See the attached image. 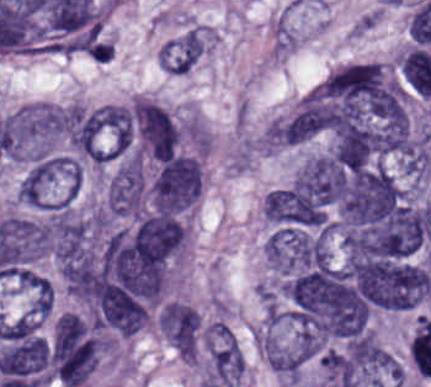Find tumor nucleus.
Masks as SVG:
<instances>
[{
  "label": "tumor nucleus",
  "mask_w": 431,
  "mask_h": 387,
  "mask_svg": "<svg viewBox=\"0 0 431 387\" xmlns=\"http://www.w3.org/2000/svg\"><path fill=\"white\" fill-rule=\"evenodd\" d=\"M196 156L174 153L158 159L144 188L154 212L189 214L194 207Z\"/></svg>",
  "instance_id": "1"
},
{
  "label": "tumor nucleus",
  "mask_w": 431,
  "mask_h": 387,
  "mask_svg": "<svg viewBox=\"0 0 431 387\" xmlns=\"http://www.w3.org/2000/svg\"><path fill=\"white\" fill-rule=\"evenodd\" d=\"M156 326L183 360H197L202 347L200 312L183 300H163L156 310Z\"/></svg>",
  "instance_id": "2"
}]
</instances>
